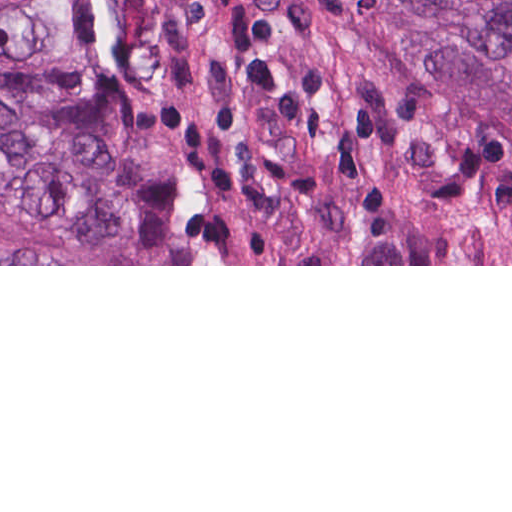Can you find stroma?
I'll list each match as a JSON object with an SVG mask.
<instances>
[{
  "mask_svg": "<svg viewBox=\"0 0 512 512\" xmlns=\"http://www.w3.org/2000/svg\"><path fill=\"white\" fill-rule=\"evenodd\" d=\"M63 77L104 109L135 264L512 266V136L383 0H88Z\"/></svg>",
  "mask_w": 512,
  "mask_h": 512,
  "instance_id": "1",
  "label": "stroma"
}]
</instances>
